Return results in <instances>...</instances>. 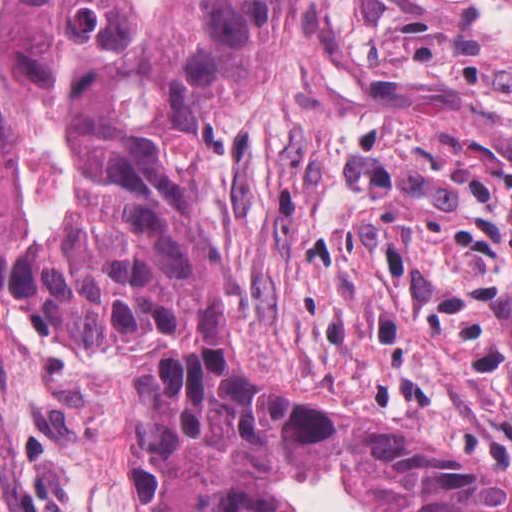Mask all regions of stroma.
Segmentation results:
<instances>
[{
  "mask_svg": "<svg viewBox=\"0 0 512 512\" xmlns=\"http://www.w3.org/2000/svg\"><path fill=\"white\" fill-rule=\"evenodd\" d=\"M262 372L512 486V0H294L206 167ZM141 334L60 353L0 288V512H155ZM378 512L352 466L276 488Z\"/></svg>",
  "mask_w": 512,
  "mask_h": 512,
  "instance_id": "obj_1",
  "label": "stroma"
}]
</instances>
